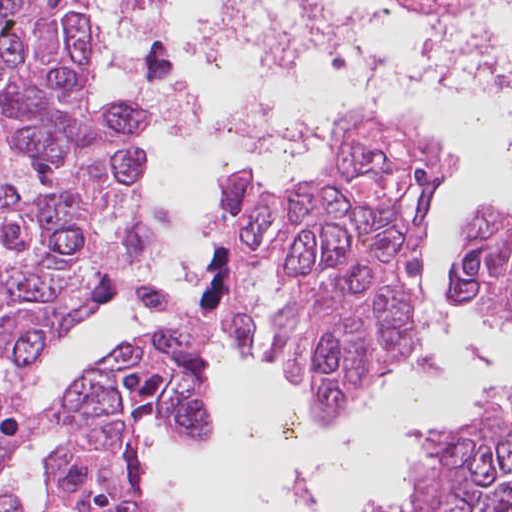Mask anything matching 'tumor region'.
<instances>
[{"instance_id":"1","label":"tumor region","mask_w":512,"mask_h":512,"mask_svg":"<svg viewBox=\"0 0 512 512\" xmlns=\"http://www.w3.org/2000/svg\"><path fill=\"white\" fill-rule=\"evenodd\" d=\"M512 313V213L478 210Z\"/></svg>"}]
</instances>
